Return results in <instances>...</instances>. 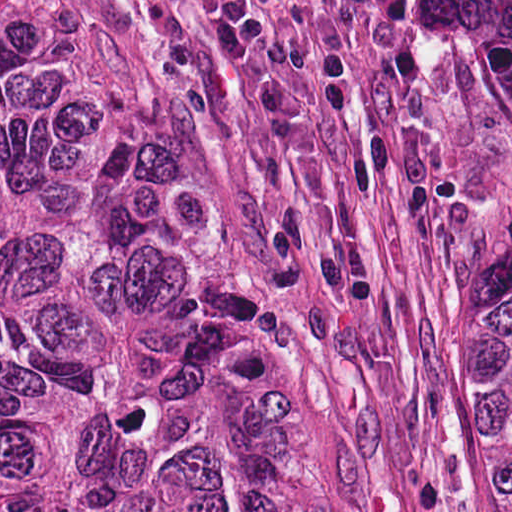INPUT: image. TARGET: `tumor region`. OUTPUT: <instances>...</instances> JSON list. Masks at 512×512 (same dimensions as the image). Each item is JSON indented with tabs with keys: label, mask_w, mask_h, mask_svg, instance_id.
<instances>
[{
	"label": "tumor region",
	"mask_w": 512,
	"mask_h": 512,
	"mask_svg": "<svg viewBox=\"0 0 512 512\" xmlns=\"http://www.w3.org/2000/svg\"><path fill=\"white\" fill-rule=\"evenodd\" d=\"M397 123L512 512V0H404ZM0 512H342L269 316L248 120L31 0H0Z\"/></svg>",
	"instance_id": "1"
}]
</instances>
